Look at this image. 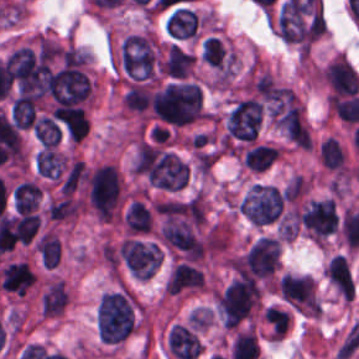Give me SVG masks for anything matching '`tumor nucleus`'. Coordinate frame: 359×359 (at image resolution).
<instances>
[{
    "instance_id": "15",
    "label": "tumor nucleus",
    "mask_w": 359,
    "mask_h": 359,
    "mask_svg": "<svg viewBox=\"0 0 359 359\" xmlns=\"http://www.w3.org/2000/svg\"><path fill=\"white\" fill-rule=\"evenodd\" d=\"M55 118L76 144L84 139L89 125L87 112L81 105L59 104Z\"/></svg>"
},
{
    "instance_id": "2",
    "label": "tumor nucleus",
    "mask_w": 359,
    "mask_h": 359,
    "mask_svg": "<svg viewBox=\"0 0 359 359\" xmlns=\"http://www.w3.org/2000/svg\"><path fill=\"white\" fill-rule=\"evenodd\" d=\"M150 106L154 118L170 125H184L205 114L201 87L189 79L170 81L154 88Z\"/></svg>"
},
{
    "instance_id": "16",
    "label": "tumor nucleus",
    "mask_w": 359,
    "mask_h": 359,
    "mask_svg": "<svg viewBox=\"0 0 359 359\" xmlns=\"http://www.w3.org/2000/svg\"><path fill=\"white\" fill-rule=\"evenodd\" d=\"M194 62V52L171 42L159 62V70L169 77L185 78L190 76Z\"/></svg>"
},
{
    "instance_id": "24",
    "label": "tumor nucleus",
    "mask_w": 359,
    "mask_h": 359,
    "mask_svg": "<svg viewBox=\"0 0 359 359\" xmlns=\"http://www.w3.org/2000/svg\"><path fill=\"white\" fill-rule=\"evenodd\" d=\"M35 137L47 146H56L61 139V128L48 116H40L33 126Z\"/></svg>"
},
{
    "instance_id": "1",
    "label": "tumor nucleus",
    "mask_w": 359,
    "mask_h": 359,
    "mask_svg": "<svg viewBox=\"0 0 359 359\" xmlns=\"http://www.w3.org/2000/svg\"><path fill=\"white\" fill-rule=\"evenodd\" d=\"M139 304L129 286L105 290L95 306V323L102 343L118 345L137 330Z\"/></svg>"
},
{
    "instance_id": "21",
    "label": "tumor nucleus",
    "mask_w": 359,
    "mask_h": 359,
    "mask_svg": "<svg viewBox=\"0 0 359 359\" xmlns=\"http://www.w3.org/2000/svg\"><path fill=\"white\" fill-rule=\"evenodd\" d=\"M35 252L40 264L46 269H53L61 254V244L56 234L47 229L42 232L36 239Z\"/></svg>"
},
{
    "instance_id": "14",
    "label": "tumor nucleus",
    "mask_w": 359,
    "mask_h": 359,
    "mask_svg": "<svg viewBox=\"0 0 359 359\" xmlns=\"http://www.w3.org/2000/svg\"><path fill=\"white\" fill-rule=\"evenodd\" d=\"M35 271L29 259H15L3 265L0 281L5 292L25 295L34 285Z\"/></svg>"
},
{
    "instance_id": "18",
    "label": "tumor nucleus",
    "mask_w": 359,
    "mask_h": 359,
    "mask_svg": "<svg viewBox=\"0 0 359 359\" xmlns=\"http://www.w3.org/2000/svg\"><path fill=\"white\" fill-rule=\"evenodd\" d=\"M280 153L279 146L255 143L243 149L241 162L252 172H262Z\"/></svg>"
},
{
    "instance_id": "19",
    "label": "tumor nucleus",
    "mask_w": 359,
    "mask_h": 359,
    "mask_svg": "<svg viewBox=\"0 0 359 359\" xmlns=\"http://www.w3.org/2000/svg\"><path fill=\"white\" fill-rule=\"evenodd\" d=\"M67 163V156L53 146H46L35 156L36 172L58 179Z\"/></svg>"
},
{
    "instance_id": "20",
    "label": "tumor nucleus",
    "mask_w": 359,
    "mask_h": 359,
    "mask_svg": "<svg viewBox=\"0 0 359 359\" xmlns=\"http://www.w3.org/2000/svg\"><path fill=\"white\" fill-rule=\"evenodd\" d=\"M41 188L30 179H23L14 185L12 200L14 211L25 213L34 211L40 200Z\"/></svg>"
},
{
    "instance_id": "3",
    "label": "tumor nucleus",
    "mask_w": 359,
    "mask_h": 359,
    "mask_svg": "<svg viewBox=\"0 0 359 359\" xmlns=\"http://www.w3.org/2000/svg\"><path fill=\"white\" fill-rule=\"evenodd\" d=\"M83 189L85 204L98 222L114 219L120 196L114 164L103 162L90 167Z\"/></svg>"
},
{
    "instance_id": "23",
    "label": "tumor nucleus",
    "mask_w": 359,
    "mask_h": 359,
    "mask_svg": "<svg viewBox=\"0 0 359 359\" xmlns=\"http://www.w3.org/2000/svg\"><path fill=\"white\" fill-rule=\"evenodd\" d=\"M200 57L215 68H223L228 65L230 53L223 41L216 35L202 38Z\"/></svg>"
},
{
    "instance_id": "12",
    "label": "tumor nucleus",
    "mask_w": 359,
    "mask_h": 359,
    "mask_svg": "<svg viewBox=\"0 0 359 359\" xmlns=\"http://www.w3.org/2000/svg\"><path fill=\"white\" fill-rule=\"evenodd\" d=\"M164 26L175 42L195 41L201 36L202 23L194 7L174 5L166 14Z\"/></svg>"
},
{
    "instance_id": "8",
    "label": "tumor nucleus",
    "mask_w": 359,
    "mask_h": 359,
    "mask_svg": "<svg viewBox=\"0 0 359 359\" xmlns=\"http://www.w3.org/2000/svg\"><path fill=\"white\" fill-rule=\"evenodd\" d=\"M299 224L315 243H324L337 230L334 198H312L298 212Z\"/></svg>"
},
{
    "instance_id": "6",
    "label": "tumor nucleus",
    "mask_w": 359,
    "mask_h": 359,
    "mask_svg": "<svg viewBox=\"0 0 359 359\" xmlns=\"http://www.w3.org/2000/svg\"><path fill=\"white\" fill-rule=\"evenodd\" d=\"M92 92V78L84 63L72 62L51 73L47 95L54 108L87 105Z\"/></svg>"
},
{
    "instance_id": "17",
    "label": "tumor nucleus",
    "mask_w": 359,
    "mask_h": 359,
    "mask_svg": "<svg viewBox=\"0 0 359 359\" xmlns=\"http://www.w3.org/2000/svg\"><path fill=\"white\" fill-rule=\"evenodd\" d=\"M124 233L149 234L153 228V216L149 207L133 199L123 213Z\"/></svg>"
},
{
    "instance_id": "22",
    "label": "tumor nucleus",
    "mask_w": 359,
    "mask_h": 359,
    "mask_svg": "<svg viewBox=\"0 0 359 359\" xmlns=\"http://www.w3.org/2000/svg\"><path fill=\"white\" fill-rule=\"evenodd\" d=\"M318 157L325 168L343 171L346 165L345 150L334 135L320 141Z\"/></svg>"
},
{
    "instance_id": "9",
    "label": "tumor nucleus",
    "mask_w": 359,
    "mask_h": 359,
    "mask_svg": "<svg viewBox=\"0 0 359 359\" xmlns=\"http://www.w3.org/2000/svg\"><path fill=\"white\" fill-rule=\"evenodd\" d=\"M277 286L282 297L298 312L320 315L321 302L314 278L304 274L284 273Z\"/></svg>"
},
{
    "instance_id": "5",
    "label": "tumor nucleus",
    "mask_w": 359,
    "mask_h": 359,
    "mask_svg": "<svg viewBox=\"0 0 359 359\" xmlns=\"http://www.w3.org/2000/svg\"><path fill=\"white\" fill-rule=\"evenodd\" d=\"M261 298L257 281L236 278L216 294L215 303L224 326L236 327L256 316Z\"/></svg>"
},
{
    "instance_id": "4",
    "label": "tumor nucleus",
    "mask_w": 359,
    "mask_h": 359,
    "mask_svg": "<svg viewBox=\"0 0 359 359\" xmlns=\"http://www.w3.org/2000/svg\"><path fill=\"white\" fill-rule=\"evenodd\" d=\"M119 62L131 80H156L159 47L153 33H127L119 43Z\"/></svg>"
},
{
    "instance_id": "11",
    "label": "tumor nucleus",
    "mask_w": 359,
    "mask_h": 359,
    "mask_svg": "<svg viewBox=\"0 0 359 359\" xmlns=\"http://www.w3.org/2000/svg\"><path fill=\"white\" fill-rule=\"evenodd\" d=\"M264 104L256 98L240 99L226 117L227 139L254 140L259 132Z\"/></svg>"
},
{
    "instance_id": "10",
    "label": "tumor nucleus",
    "mask_w": 359,
    "mask_h": 359,
    "mask_svg": "<svg viewBox=\"0 0 359 359\" xmlns=\"http://www.w3.org/2000/svg\"><path fill=\"white\" fill-rule=\"evenodd\" d=\"M117 250L133 278H150L161 261V249L153 241L126 237Z\"/></svg>"
},
{
    "instance_id": "7",
    "label": "tumor nucleus",
    "mask_w": 359,
    "mask_h": 359,
    "mask_svg": "<svg viewBox=\"0 0 359 359\" xmlns=\"http://www.w3.org/2000/svg\"><path fill=\"white\" fill-rule=\"evenodd\" d=\"M284 195L275 186L252 182L237 202L240 215L253 224H267L280 216Z\"/></svg>"
},
{
    "instance_id": "13",
    "label": "tumor nucleus",
    "mask_w": 359,
    "mask_h": 359,
    "mask_svg": "<svg viewBox=\"0 0 359 359\" xmlns=\"http://www.w3.org/2000/svg\"><path fill=\"white\" fill-rule=\"evenodd\" d=\"M205 288V273L199 266L184 260H176L169 271L163 292L165 295H175Z\"/></svg>"
}]
</instances>
